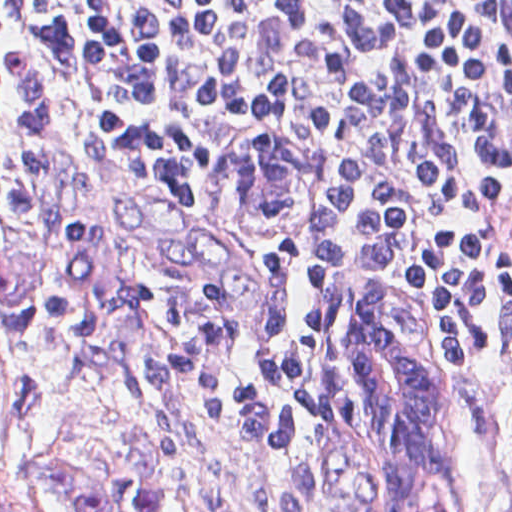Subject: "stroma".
<instances>
[{"mask_svg":"<svg viewBox=\"0 0 512 512\" xmlns=\"http://www.w3.org/2000/svg\"><path fill=\"white\" fill-rule=\"evenodd\" d=\"M255 134H282L300 152V200L288 218L236 209L233 153ZM353 171V131L285 106L239 105L215 141L201 321L226 348L229 384L201 393L231 419L41 296L0 237V512H78L42 494L38 462L76 458L114 475L150 443L165 450L168 512H371L354 486L368 385L355 370L350 319L358 296L379 285L408 296L418 338L443 374L444 512H512V347L430 323L404 251L370 247L340 305L338 365L324 399L305 402L247 356L242 321L263 243L330 205Z\"/></svg>","mask_w":512,"mask_h":512,"instance_id":"obj_1","label":"stroma"}]
</instances>
